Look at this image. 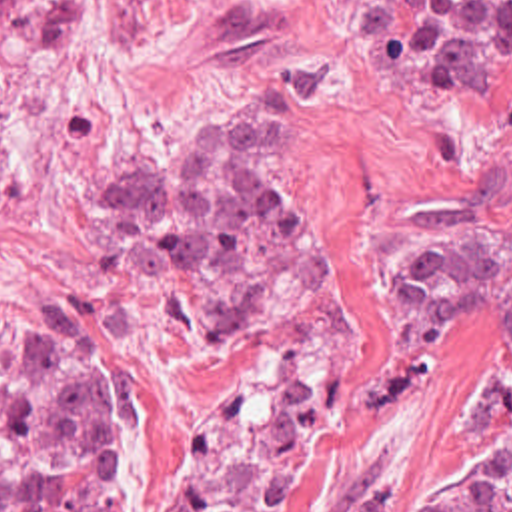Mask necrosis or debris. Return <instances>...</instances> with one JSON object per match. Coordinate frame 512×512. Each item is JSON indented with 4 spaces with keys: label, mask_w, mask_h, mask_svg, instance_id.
<instances>
[{
    "label": "necrosis or debris",
    "mask_w": 512,
    "mask_h": 512,
    "mask_svg": "<svg viewBox=\"0 0 512 512\" xmlns=\"http://www.w3.org/2000/svg\"><path fill=\"white\" fill-rule=\"evenodd\" d=\"M315 427L313 387L291 379L251 393L201 431L165 512H273Z\"/></svg>",
    "instance_id": "necrosis-or-debris-1"
}]
</instances>
